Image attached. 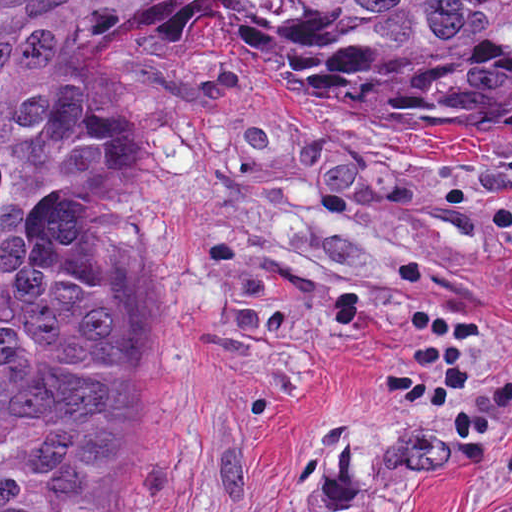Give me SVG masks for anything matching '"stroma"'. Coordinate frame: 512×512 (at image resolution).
<instances>
[{
	"mask_svg": "<svg viewBox=\"0 0 512 512\" xmlns=\"http://www.w3.org/2000/svg\"><path fill=\"white\" fill-rule=\"evenodd\" d=\"M52 236L136 323L112 512H512V142L317 93L170 1L78 80Z\"/></svg>",
	"mask_w": 512,
	"mask_h": 512,
	"instance_id": "stroma-1",
	"label": "stroma"
}]
</instances>
